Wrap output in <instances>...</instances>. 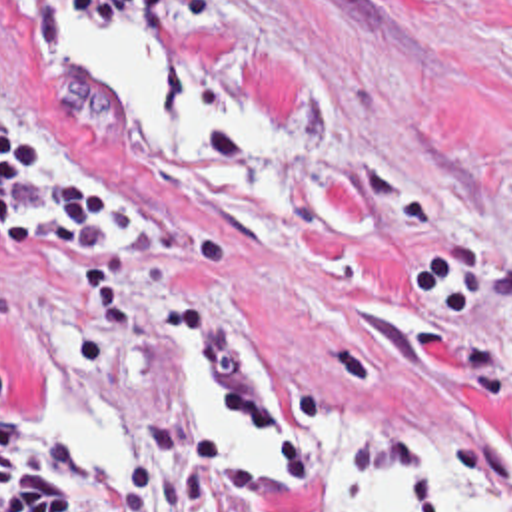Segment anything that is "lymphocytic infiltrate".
<instances>
[{
	"mask_svg": "<svg viewBox=\"0 0 512 512\" xmlns=\"http://www.w3.org/2000/svg\"><path fill=\"white\" fill-rule=\"evenodd\" d=\"M154 215L132 187L82 167H50L40 139L0 112V247L6 257H70L90 281L82 357L102 363L142 337V311L118 247L150 239ZM46 425L12 411L0 365V512H256L258 471L182 427L142 419L138 449L114 479H90ZM441 512L425 479L406 489Z\"/></svg>",
	"mask_w": 512,
	"mask_h": 512,
	"instance_id": "1",
	"label": "lymphocytic infiltrate"
}]
</instances>
